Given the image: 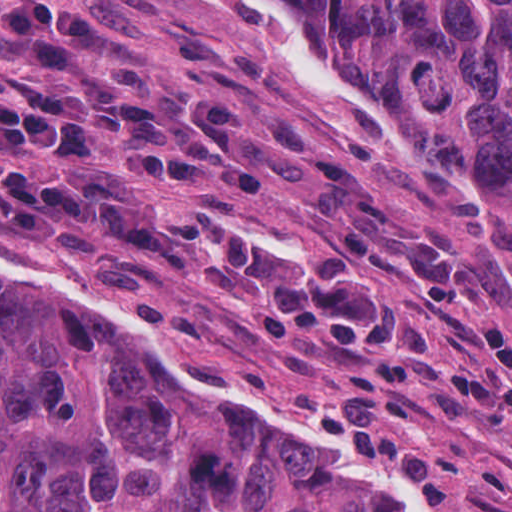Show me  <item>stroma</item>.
<instances>
[{
    "mask_svg": "<svg viewBox=\"0 0 512 512\" xmlns=\"http://www.w3.org/2000/svg\"><path fill=\"white\" fill-rule=\"evenodd\" d=\"M68 1L105 17L109 34L92 58L102 70L136 59L152 71L161 103L176 109L243 105L242 140L267 175V194L248 197L204 171L193 197H175L116 174L111 141H96L79 168L28 161L3 144L0 160L56 182L88 172L118 182L178 234L246 219L272 242L371 266L403 299L412 343L401 373L417 399L390 417L447 469L456 504L442 511L512 512V228L475 183L427 141L390 127L356 66L347 63L368 105H344L276 54L153 1ZM57 70L0 31V93L15 89V73L48 79ZM0 242L106 287L201 369L344 440L345 386L367 359L335 358L315 336L280 341L234 280L168 273L123 288L108 282L98 250L33 248L1 216Z\"/></svg>",
    "mask_w": 512,
    "mask_h": 512,
    "instance_id": "1",
    "label": "stroma"
}]
</instances>
